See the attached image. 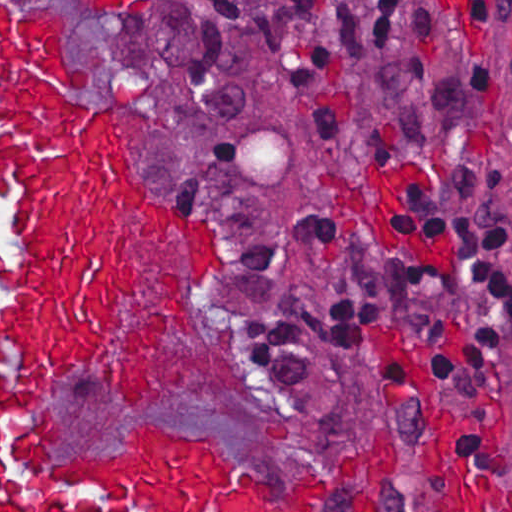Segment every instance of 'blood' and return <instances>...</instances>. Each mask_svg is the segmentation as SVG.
I'll list each match as a JSON object with an SVG mask.
<instances>
[{
  "instance_id": "1a1defca",
  "label": "blood",
  "mask_w": 512,
  "mask_h": 512,
  "mask_svg": "<svg viewBox=\"0 0 512 512\" xmlns=\"http://www.w3.org/2000/svg\"><path fill=\"white\" fill-rule=\"evenodd\" d=\"M119 7L129 0H91ZM65 11L1 8V191L18 190L1 267V512H206L235 478L209 435L139 424L104 455L52 451L67 427L42 402L74 372L104 379L129 407L155 395L172 323L204 340L200 288L177 272L148 305L141 296L139 219L175 233L204 274L218 244L146 194L127 170L112 112L75 94L90 71L64 56ZM375 339L429 428V468L442 512H512V484L473 476L453 445L439 393L404 341ZM330 474L274 512H319ZM219 512H271L225 496Z\"/></svg>"
}]
</instances>
